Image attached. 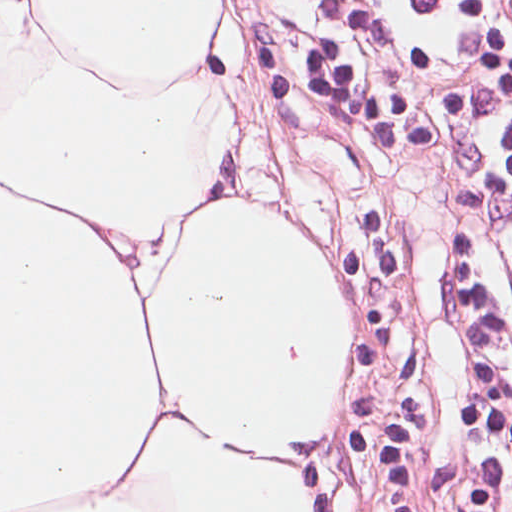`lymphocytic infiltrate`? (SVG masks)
<instances>
[{"label": "lymphocytic infiltrate", "mask_w": 512, "mask_h": 512, "mask_svg": "<svg viewBox=\"0 0 512 512\" xmlns=\"http://www.w3.org/2000/svg\"><path fill=\"white\" fill-rule=\"evenodd\" d=\"M389 501L512 512V0H495Z\"/></svg>", "instance_id": "1"}]
</instances>
